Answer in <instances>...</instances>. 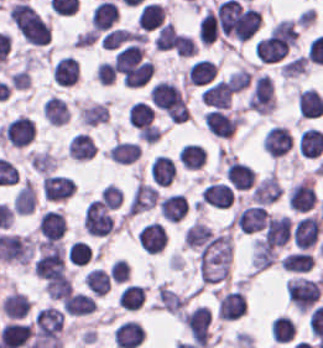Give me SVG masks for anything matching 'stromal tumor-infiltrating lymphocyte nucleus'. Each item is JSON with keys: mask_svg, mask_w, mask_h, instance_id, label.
I'll list each match as a JSON object with an SVG mask.
<instances>
[{"mask_svg": "<svg viewBox=\"0 0 323 348\" xmlns=\"http://www.w3.org/2000/svg\"><path fill=\"white\" fill-rule=\"evenodd\" d=\"M220 31L215 10L207 8L198 27V37L204 43H211Z\"/></svg>", "mask_w": 323, "mask_h": 348, "instance_id": "31", "label": "stromal tumor-infiltrating lymphocyte nucleus"}, {"mask_svg": "<svg viewBox=\"0 0 323 348\" xmlns=\"http://www.w3.org/2000/svg\"><path fill=\"white\" fill-rule=\"evenodd\" d=\"M175 175V166L171 158L164 154H157L151 162L150 176L152 182L158 186H168Z\"/></svg>", "mask_w": 323, "mask_h": 348, "instance_id": "19", "label": "stromal tumor-infiltrating lymphocyte nucleus"}, {"mask_svg": "<svg viewBox=\"0 0 323 348\" xmlns=\"http://www.w3.org/2000/svg\"><path fill=\"white\" fill-rule=\"evenodd\" d=\"M308 66L309 61L307 53H300L283 63L280 70L281 74L285 76H292L307 71Z\"/></svg>", "mask_w": 323, "mask_h": 348, "instance_id": "38", "label": "stromal tumor-infiltrating lymphocyte nucleus"}, {"mask_svg": "<svg viewBox=\"0 0 323 348\" xmlns=\"http://www.w3.org/2000/svg\"><path fill=\"white\" fill-rule=\"evenodd\" d=\"M322 226L319 214H306L299 219L292 231V238L298 248H312L318 241Z\"/></svg>", "mask_w": 323, "mask_h": 348, "instance_id": "3", "label": "stromal tumor-infiltrating lymphocyte nucleus"}, {"mask_svg": "<svg viewBox=\"0 0 323 348\" xmlns=\"http://www.w3.org/2000/svg\"><path fill=\"white\" fill-rule=\"evenodd\" d=\"M193 37L177 31L174 50L179 57H190L197 50Z\"/></svg>", "mask_w": 323, "mask_h": 348, "instance_id": "40", "label": "stromal tumor-infiltrating lymphocyte nucleus"}, {"mask_svg": "<svg viewBox=\"0 0 323 348\" xmlns=\"http://www.w3.org/2000/svg\"><path fill=\"white\" fill-rule=\"evenodd\" d=\"M61 308L68 315L84 316L96 310V301L86 292L73 291L61 301Z\"/></svg>", "mask_w": 323, "mask_h": 348, "instance_id": "14", "label": "stromal tumor-infiltrating lymphocyte nucleus"}, {"mask_svg": "<svg viewBox=\"0 0 323 348\" xmlns=\"http://www.w3.org/2000/svg\"><path fill=\"white\" fill-rule=\"evenodd\" d=\"M165 7L155 1L141 5L136 16L137 24L143 31H151L164 20Z\"/></svg>", "mask_w": 323, "mask_h": 348, "instance_id": "18", "label": "stromal tumor-infiltrating lymphocyte nucleus"}, {"mask_svg": "<svg viewBox=\"0 0 323 348\" xmlns=\"http://www.w3.org/2000/svg\"><path fill=\"white\" fill-rule=\"evenodd\" d=\"M120 17V10L112 1H99L91 14L90 24L96 31H106Z\"/></svg>", "mask_w": 323, "mask_h": 348, "instance_id": "11", "label": "stromal tumor-infiltrating lymphocyte nucleus"}, {"mask_svg": "<svg viewBox=\"0 0 323 348\" xmlns=\"http://www.w3.org/2000/svg\"><path fill=\"white\" fill-rule=\"evenodd\" d=\"M137 240L147 253H158L165 246L164 224L157 222L146 223L138 232Z\"/></svg>", "mask_w": 323, "mask_h": 348, "instance_id": "7", "label": "stromal tumor-infiltrating lymphocyte nucleus"}, {"mask_svg": "<svg viewBox=\"0 0 323 348\" xmlns=\"http://www.w3.org/2000/svg\"><path fill=\"white\" fill-rule=\"evenodd\" d=\"M225 172L229 183L236 188H248L255 175L253 167L248 162L235 157L228 161Z\"/></svg>", "mask_w": 323, "mask_h": 348, "instance_id": "16", "label": "stromal tumor-infiltrating lymphocyte nucleus"}, {"mask_svg": "<svg viewBox=\"0 0 323 348\" xmlns=\"http://www.w3.org/2000/svg\"><path fill=\"white\" fill-rule=\"evenodd\" d=\"M86 233L96 236H105L112 233L115 223L98 199H91L87 204L82 221Z\"/></svg>", "mask_w": 323, "mask_h": 348, "instance_id": "1", "label": "stromal tumor-infiltrating lymphocyte nucleus"}, {"mask_svg": "<svg viewBox=\"0 0 323 348\" xmlns=\"http://www.w3.org/2000/svg\"><path fill=\"white\" fill-rule=\"evenodd\" d=\"M264 141L266 151L277 157L293 146L292 133L286 125H272L264 135Z\"/></svg>", "mask_w": 323, "mask_h": 348, "instance_id": "6", "label": "stromal tumor-infiltrating lymphocyte nucleus"}, {"mask_svg": "<svg viewBox=\"0 0 323 348\" xmlns=\"http://www.w3.org/2000/svg\"><path fill=\"white\" fill-rule=\"evenodd\" d=\"M298 106L301 116H315L323 110V97L318 89L307 87L298 93Z\"/></svg>", "mask_w": 323, "mask_h": 348, "instance_id": "23", "label": "stromal tumor-infiltrating lymphocyte nucleus"}, {"mask_svg": "<svg viewBox=\"0 0 323 348\" xmlns=\"http://www.w3.org/2000/svg\"><path fill=\"white\" fill-rule=\"evenodd\" d=\"M206 150L199 142H185L179 149L178 160L187 169H196L204 164Z\"/></svg>", "mask_w": 323, "mask_h": 348, "instance_id": "24", "label": "stromal tumor-infiltrating lymphocyte nucleus"}, {"mask_svg": "<svg viewBox=\"0 0 323 348\" xmlns=\"http://www.w3.org/2000/svg\"><path fill=\"white\" fill-rule=\"evenodd\" d=\"M38 227L42 235L49 240L61 238L66 228L65 215L55 208H48L39 216Z\"/></svg>", "mask_w": 323, "mask_h": 348, "instance_id": "12", "label": "stromal tumor-infiltrating lymphocyte nucleus"}, {"mask_svg": "<svg viewBox=\"0 0 323 348\" xmlns=\"http://www.w3.org/2000/svg\"><path fill=\"white\" fill-rule=\"evenodd\" d=\"M75 186L70 176L59 173H45L42 180V192L47 199H66L72 194Z\"/></svg>", "mask_w": 323, "mask_h": 348, "instance_id": "5", "label": "stromal tumor-infiltrating lymphocyte nucleus"}, {"mask_svg": "<svg viewBox=\"0 0 323 348\" xmlns=\"http://www.w3.org/2000/svg\"><path fill=\"white\" fill-rule=\"evenodd\" d=\"M298 148L302 156L311 158L323 152V130L308 126L300 134Z\"/></svg>", "mask_w": 323, "mask_h": 348, "instance_id": "20", "label": "stromal tumor-infiltrating lymphocyte nucleus"}, {"mask_svg": "<svg viewBox=\"0 0 323 348\" xmlns=\"http://www.w3.org/2000/svg\"><path fill=\"white\" fill-rule=\"evenodd\" d=\"M130 38L131 36L127 27L115 26L104 32L100 41L102 47L106 49H115Z\"/></svg>", "mask_w": 323, "mask_h": 348, "instance_id": "37", "label": "stromal tumor-infiltrating lymphocyte nucleus"}, {"mask_svg": "<svg viewBox=\"0 0 323 348\" xmlns=\"http://www.w3.org/2000/svg\"><path fill=\"white\" fill-rule=\"evenodd\" d=\"M188 209L189 202L184 193L173 192L159 199V212L167 220L178 222Z\"/></svg>", "mask_w": 323, "mask_h": 348, "instance_id": "13", "label": "stromal tumor-infiltrating lymphocyte nucleus"}, {"mask_svg": "<svg viewBox=\"0 0 323 348\" xmlns=\"http://www.w3.org/2000/svg\"><path fill=\"white\" fill-rule=\"evenodd\" d=\"M234 92L229 80L220 79L203 90V101L209 105L220 108H228Z\"/></svg>", "mask_w": 323, "mask_h": 348, "instance_id": "15", "label": "stromal tumor-infiltrating lymphocyte nucleus"}, {"mask_svg": "<svg viewBox=\"0 0 323 348\" xmlns=\"http://www.w3.org/2000/svg\"><path fill=\"white\" fill-rule=\"evenodd\" d=\"M84 281L94 295H103L111 284V276L95 266L86 273Z\"/></svg>", "mask_w": 323, "mask_h": 348, "instance_id": "32", "label": "stromal tumor-infiltrating lymphocyte nucleus"}, {"mask_svg": "<svg viewBox=\"0 0 323 348\" xmlns=\"http://www.w3.org/2000/svg\"><path fill=\"white\" fill-rule=\"evenodd\" d=\"M144 297L143 285L127 283L123 285L119 300L120 305L125 308L137 309Z\"/></svg>", "mask_w": 323, "mask_h": 348, "instance_id": "35", "label": "stromal tumor-infiltrating lymphocyte nucleus"}, {"mask_svg": "<svg viewBox=\"0 0 323 348\" xmlns=\"http://www.w3.org/2000/svg\"><path fill=\"white\" fill-rule=\"evenodd\" d=\"M29 161L37 172H50L54 169L56 159L50 151L30 150Z\"/></svg>", "mask_w": 323, "mask_h": 348, "instance_id": "36", "label": "stromal tumor-infiltrating lymphocyte nucleus"}, {"mask_svg": "<svg viewBox=\"0 0 323 348\" xmlns=\"http://www.w3.org/2000/svg\"><path fill=\"white\" fill-rule=\"evenodd\" d=\"M44 288L53 300H62L69 296L72 284L71 280L63 274L45 280Z\"/></svg>", "mask_w": 323, "mask_h": 348, "instance_id": "33", "label": "stromal tumor-infiltrating lymphocyte nucleus"}, {"mask_svg": "<svg viewBox=\"0 0 323 348\" xmlns=\"http://www.w3.org/2000/svg\"><path fill=\"white\" fill-rule=\"evenodd\" d=\"M296 333V326L291 317L277 315L271 322V338L278 342H286Z\"/></svg>", "mask_w": 323, "mask_h": 348, "instance_id": "30", "label": "stromal tumor-infiltrating lymphocyte nucleus"}, {"mask_svg": "<svg viewBox=\"0 0 323 348\" xmlns=\"http://www.w3.org/2000/svg\"><path fill=\"white\" fill-rule=\"evenodd\" d=\"M216 71V63L211 58H198L188 66L189 83H209L214 79Z\"/></svg>", "mask_w": 323, "mask_h": 348, "instance_id": "22", "label": "stromal tumor-infiltrating lymphocyte nucleus"}, {"mask_svg": "<svg viewBox=\"0 0 323 348\" xmlns=\"http://www.w3.org/2000/svg\"><path fill=\"white\" fill-rule=\"evenodd\" d=\"M143 328L137 320H123L114 330L115 343L120 348H134L142 341Z\"/></svg>", "mask_w": 323, "mask_h": 348, "instance_id": "10", "label": "stromal tumor-infiltrating lymphocyte nucleus"}, {"mask_svg": "<svg viewBox=\"0 0 323 348\" xmlns=\"http://www.w3.org/2000/svg\"><path fill=\"white\" fill-rule=\"evenodd\" d=\"M177 30L172 21H164L155 32L153 43L154 48H174Z\"/></svg>", "mask_w": 323, "mask_h": 348, "instance_id": "34", "label": "stromal tumor-infiltrating lymphocyte nucleus"}, {"mask_svg": "<svg viewBox=\"0 0 323 348\" xmlns=\"http://www.w3.org/2000/svg\"><path fill=\"white\" fill-rule=\"evenodd\" d=\"M107 117L106 101H94L79 107L81 124L96 125Z\"/></svg>", "mask_w": 323, "mask_h": 348, "instance_id": "29", "label": "stromal tumor-infiltrating lymphocyte nucleus"}, {"mask_svg": "<svg viewBox=\"0 0 323 348\" xmlns=\"http://www.w3.org/2000/svg\"><path fill=\"white\" fill-rule=\"evenodd\" d=\"M53 75L59 85H72L80 76L79 59L75 56H61L53 67Z\"/></svg>", "mask_w": 323, "mask_h": 348, "instance_id": "17", "label": "stromal tumor-infiltrating lymphocyte nucleus"}, {"mask_svg": "<svg viewBox=\"0 0 323 348\" xmlns=\"http://www.w3.org/2000/svg\"><path fill=\"white\" fill-rule=\"evenodd\" d=\"M200 199L204 203L228 207L235 200V191L229 183L214 181L209 183L201 192Z\"/></svg>", "mask_w": 323, "mask_h": 348, "instance_id": "8", "label": "stromal tumor-infiltrating lymphocyte nucleus"}, {"mask_svg": "<svg viewBox=\"0 0 323 348\" xmlns=\"http://www.w3.org/2000/svg\"><path fill=\"white\" fill-rule=\"evenodd\" d=\"M66 148L68 156L85 160L94 155L95 142L85 131H78L68 140Z\"/></svg>", "mask_w": 323, "mask_h": 348, "instance_id": "21", "label": "stromal tumor-infiltrating lymphocyte nucleus"}, {"mask_svg": "<svg viewBox=\"0 0 323 348\" xmlns=\"http://www.w3.org/2000/svg\"><path fill=\"white\" fill-rule=\"evenodd\" d=\"M36 191L31 181H24L14 196L13 210L17 214H30L35 208Z\"/></svg>", "mask_w": 323, "mask_h": 348, "instance_id": "25", "label": "stromal tumor-infiltrating lymphocyte nucleus"}, {"mask_svg": "<svg viewBox=\"0 0 323 348\" xmlns=\"http://www.w3.org/2000/svg\"><path fill=\"white\" fill-rule=\"evenodd\" d=\"M94 73L99 83H112L115 76V66L108 59H101L95 66Z\"/></svg>", "mask_w": 323, "mask_h": 348, "instance_id": "41", "label": "stromal tumor-infiltrating lymphocyte nucleus"}, {"mask_svg": "<svg viewBox=\"0 0 323 348\" xmlns=\"http://www.w3.org/2000/svg\"><path fill=\"white\" fill-rule=\"evenodd\" d=\"M127 116L131 123L144 129L153 122V105L147 101L135 100L132 102Z\"/></svg>", "mask_w": 323, "mask_h": 348, "instance_id": "27", "label": "stromal tumor-infiltrating lymphocyte nucleus"}, {"mask_svg": "<svg viewBox=\"0 0 323 348\" xmlns=\"http://www.w3.org/2000/svg\"><path fill=\"white\" fill-rule=\"evenodd\" d=\"M204 120L214 135L227 137L239 125L240 116L215 106Z\"/></svg>", "mask_w": 323, "mask_h": 348, "instance_id": "4", "label": "stromal tumor-infiltrating lymphocyte nucleus"}, {"mask_svg": "<svg viewBox=\"0 0 323 348\" xmlns=\"http://www.w3.org/2000/svg\"><path fill=\"white\" fill-rule=\"evenodd\" d=\"M141 152V145L134 141L129 140H116L110 150L107 152V156L115 161L119 162H132Z\"/></svg>", "mask_w": 323, "mask_h": 348, "instance_id": "26", "label": "stromal tumor-infiltrating lymphocyte nucleus"}, {"mask_svg": "<svg viewBox=\"0 0 323 348\" xmlns=\"http://www.w3.org/2000/svg\"><path fill=\"white\" fill-rule=\"evenodd\" d=\"M100 197L107 209H115L123 200V191L121 187L110 182L102 188Z\"/></svg>", "mask_w": 323, "mask_h": 348, "instance_id": "39", "label": "stromal tumor-infiltrating lymphocyte nucleus"}, {"mask_svg": "<svg viewBox=\"0 0 323 348\" xmlns=\"http://www.w3.org/2000/svg\"><path fill=\"white\" fill-rule=\"evenodd\" d=\"M218 312L220 318L235 320L246 313V299L239 288L229 291L219 301Z\"/></svg>", "mask_w": 323, "mask_h": 348, "instance_id": "9", "label": "stromal tumor-infiltrating lymphocyte nucleus"}, {"mask_svg": "<svg viewBox=\"0 0 323 348\" xmlns=\"http://www.w3.org/2000/svg\"><path fill=\"white\" fill-rule=\"evenodd\" d=\"M43 113L47 120L59 125L70 117L63 99L53 94L44 101Z\"/></svg>", "mask_w": 323, "mask_h": 348, "instance_id": "28", "label": "stromal tumor-infiltrating lymphocyte nucleus"}, {"mask_svg": "<svg viewBox=\"0 0 323 348\" xmlns=\"http://www.w3.org/2000/svg\"><path fill=\"white\" fill-rule=\"evenodd\" d=\"M1 136L12 145L22 147L35 137L33 118L27 114L17 115L2 126Z\"/></svg>", "mask_w": 323, "mask_h": 348, "instance_id": "2", "label": "stromal tumor-infiltrating lymphocyte nucleus"}]
</instances>
